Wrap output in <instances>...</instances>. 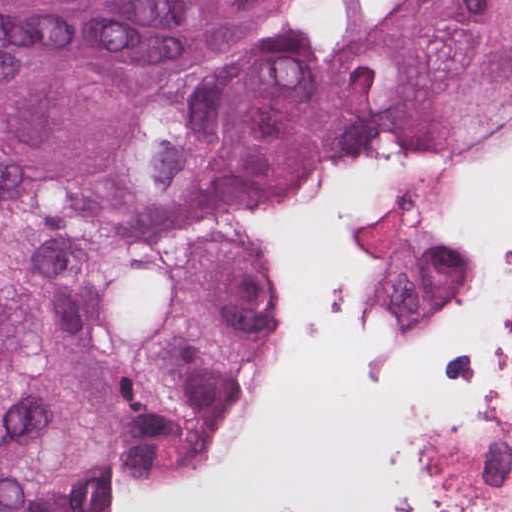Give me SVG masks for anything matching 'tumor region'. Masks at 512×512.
I'll return each mask as SVG.
<instances>
[{
    "instance_id": "1",
    "label": "tumor region",
    "mask_w": 512,
    "mask_h": 512,
    "mask_svg": "<svg viewBox=\"0 0 512 512\" xmlns=\"http://www.w3.org/2000/svg\"><path fill=\"white\" fill-rule=\"evenodd\" d=\"M512 122V0H0V512H136L227 439L281 292L227 192L286 151Z\"/></svg>"
}]
</instances>
